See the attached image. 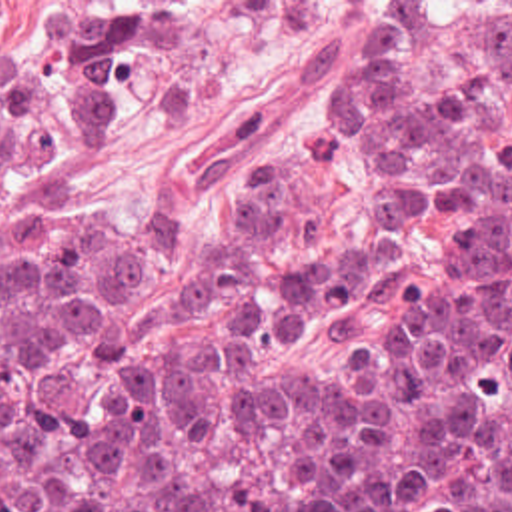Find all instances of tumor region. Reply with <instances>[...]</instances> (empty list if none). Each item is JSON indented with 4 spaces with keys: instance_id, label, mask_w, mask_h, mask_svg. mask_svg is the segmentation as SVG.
Returning <instances> with one entry per match:
<instances>
[{
    "instance_id": "e687c5a6",
    "label": "tumor region",
    "mask_w": 512,
    "mask_h": 512,
    "mask_svg": "<svg viewBox=\"0 0 512 512\" xmlns=\"http://www.w3.org/2000/svg\"><path fill=\"white\" fill-rule=\"evenodd\" d=\"M170 0H74L0 50V512H512V0H338L306 66L226 140H150L138 102ZM336 46L326 156L360 152L428 264L356 296L292 154L254 152L214 214L52 220L60 160L132 128L174 174L260 138Z\"/></svg>"
}]
</instances>
